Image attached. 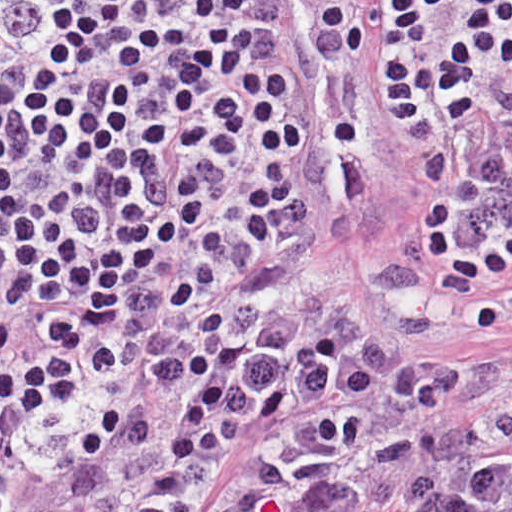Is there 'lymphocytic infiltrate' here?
Segmentation results:
<instances>
[{"label":"lymphocytic infiltrate","instance_id":"1","mask_svg":"<svg viewBox=\"0 0 512 512\" xmlns=\"http://www.w3.org/2000/svg\"><path fill=\"white\" fill-rule=\"evenodd\" d=\"M293 2L316 18L311 58L359 56L320 0ZM486 4L512 71V0ZM275 15L273 0H0V512L22 500L92 359L124 377L216 261L312 227L314 206L287 179L305 131ZM371 83L382 104L372 73ZM491 117L485 97L456 126L406 136L426 144ZM208 139L253 185L259 221L248 232L174 209L176 167ZM511 149L512 123L474 150L427 157L416 177L423 227L437 229ZM122 458L123 411L111 405L79 461L92 478H121Z\"/></svg>","mask_w":512,"mask_h":512}]
</instances>
